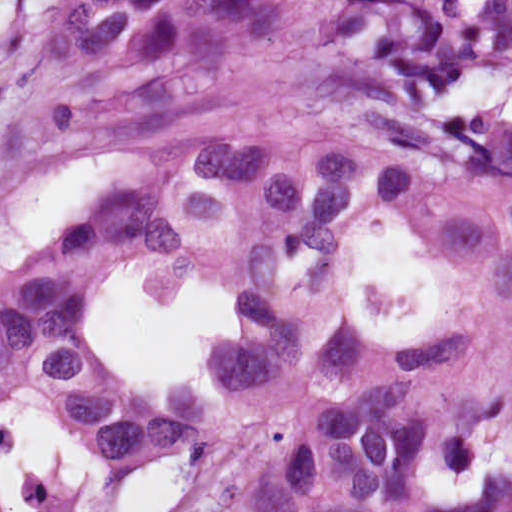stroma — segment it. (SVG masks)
<instances>
[{"label":"stroma","instance_id":"obj_1","mask_svg":"<svg viewBox=\"0 0 512 512\" xmlns=\"http://www.w3.org/2000/svg\"><path fill=\"white\" fill-rule=\"evenodd\" d=\"M11 1L14 18L0 41V80L13 69L22 49L59 0ZM469 86L481 118L491 128H512V62L480 73ZM65 162L32 160L0 174V228L14 200L42 172ZM137 262L161 267V285L173 297L184 294L200 281L218 282L212 279L176 281L165 267ZM420 274L426 276V286L416 312L400 319L381 317L378 323L370 321L365 284L381 277L401 289ZM441 294V277L435 265L423 254L383 229L380 222L365 231L348 305L354 327L371 332L384 344L400 343L434 309ZM227 341L217 347V356ZM509 357H512V321L452 347L447 363L454 374H462L485 370ZM217 371L221 386L222 372L218 362ZM301 391L302 379L279 387H255L231 428L214 445L194 455L200 459L199 490L168 512H231L239 473L288 427L298 409ZM53 422L69 440L65 429ZM501 441L471 447L440 465ZM30 491L38 512H102L89 498L67 497L53 477L45 472L35 475ZM431 512H512V477L492 480L467 497L447 496L441 508Z\"/></svg>","mask_w":512,"mask_h":512}]
</instances>
